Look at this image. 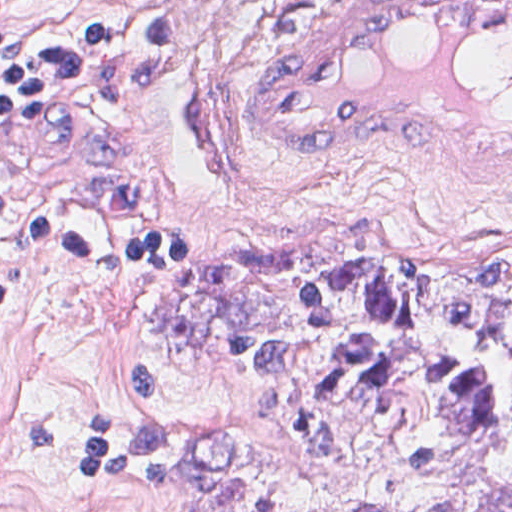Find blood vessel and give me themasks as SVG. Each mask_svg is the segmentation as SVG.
Masks as SVG:
<instances>
[{
  "label": "blood vessel",
  "instance_id": "8fb6f2fc",
  "mask_svg": "<svg viewBox=\"0 0 512 512\" xmlns=\"http://www.w3.org/2000/svg\"><path fill=\"white\" fill-rule=\"evenodd\" d=\"M242 122L273 153L415 155L512 190V1H295L259 49Z\"/></svg>",
  "mask_w": 512,
  "mask_h": 512
}]
</instances>
